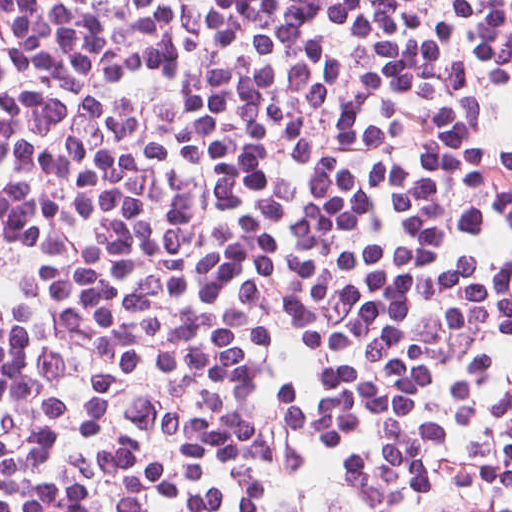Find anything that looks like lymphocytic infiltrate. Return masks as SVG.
<instances>
[{
	"mask_svg": "<svg viewBox=\"0 0 512 512\" xmlns=\"http://www.w3.org/2000/svg\"><path fill=\"white\" fill-rule=\"evenodd\" d=\"M0 512H512V0H0Z\"/></svg>",
	"mask_w": 512,
	"mask_h": 512,
	"instance_id": "1",
	"label": "lymphocytic infiltrate"
}]
</instances>
